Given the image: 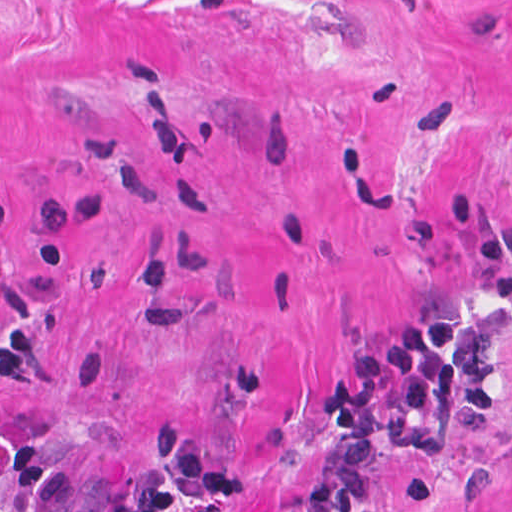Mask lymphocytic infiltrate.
Instances as JSON below:
<instances>
[{
    "label": "lymphocytic infiltrate",
    "instance_id": "obj_1",
    "mask_svg": "<svg viewBox=\"0 0 512 512\" xmlns=\"http://www.w3.org/2000/svg\"><path fill=\"white\" fill-rule=\"evenodd\" d=\"M462 314L413 315L367 341L333 384L309 430L311 474L295 512H363L375 465L398 425L436 417L454 384ZM156 454L191 503L212 512H267L245 473L199 425H173Z\"/></svg>",
    "mask_w": 512,
    "mask_h": 512
}]
</instances>
